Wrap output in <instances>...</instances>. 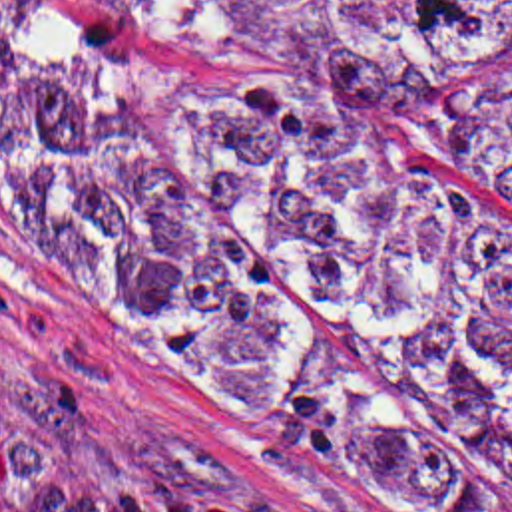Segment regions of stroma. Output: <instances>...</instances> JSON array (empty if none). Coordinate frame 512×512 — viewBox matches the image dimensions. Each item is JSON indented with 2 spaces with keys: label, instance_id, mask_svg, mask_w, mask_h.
Returning <instances> with one entry per match:
<instances>
[{
  "label": "stroma",
  "instance_id": "obj_1",
  "mask_svg": "<svg viewBox=\"0 0 512 512\" xmlns=\"http://www.w3.org/2000/svg\"><path fill=\"white\" fill-rule=\"evenodd\" d=\"M249 61L241 41L132 1L0 0V87ZM380 122L428 196L512 240L510 194L400 148ZM0 395L94 465L183 479L265 512H512L380 485L235 417L82 280L2 160Z\"/></svg>",
  "mask_w": 512,
  "mask_h": 512
}]
</instances>
